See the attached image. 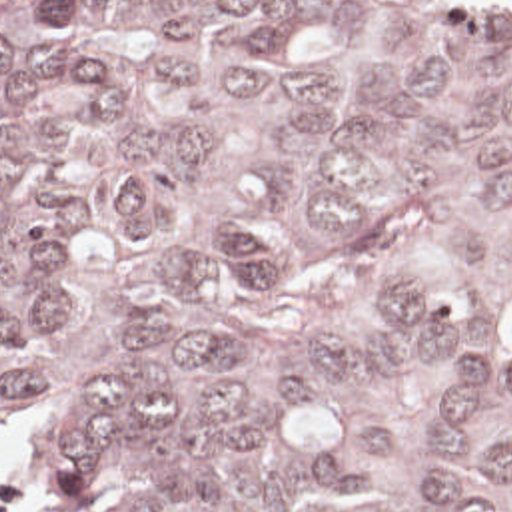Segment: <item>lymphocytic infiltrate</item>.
Instances as JSON below:
<instances>
[{
  "label": "lymphocytic infiltrate",
  "instance_id": "1",
  "mask_svg": "<svg viewBox=\"0 0 512 512\" xmlns=\"http://www.w3.org/2000/svg\"><path fill=\"white\" fill-rule=\"evenodd\" d=\"M26 504L24 478L0 468V512H22Z\"/></svg>",
  "mask_w": 512,
  "mask_h": 512
}]
</instances>
